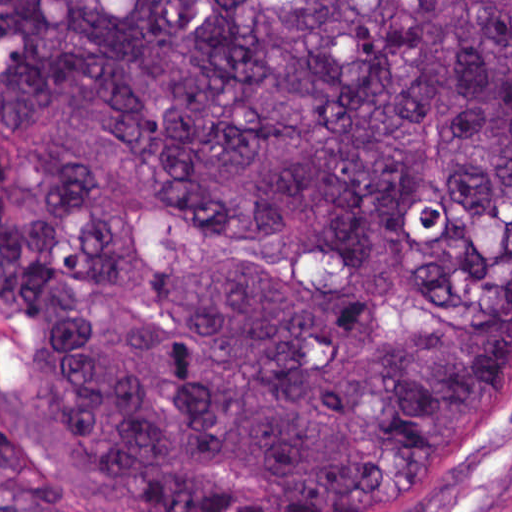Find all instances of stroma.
Listing matches in <instances>:
<instances>
[{"instance_id": "1", "label": "stroma", "mask_w": 512, "mask_h": 512, "mask_svg": "<svg viewBox=\"0 0 512 512\" xmlns=\"http://www.w3.org/2000/svg\"><path fill=\"white\" fill-rule=\"evenodd\" d=\"M25 398L23 364L0 329V418L25 422L81 480L123 512H134L74 455L17 413ZM402 512H512V344L501 366L489 423Z\"/></svg>"}]
</instances>
